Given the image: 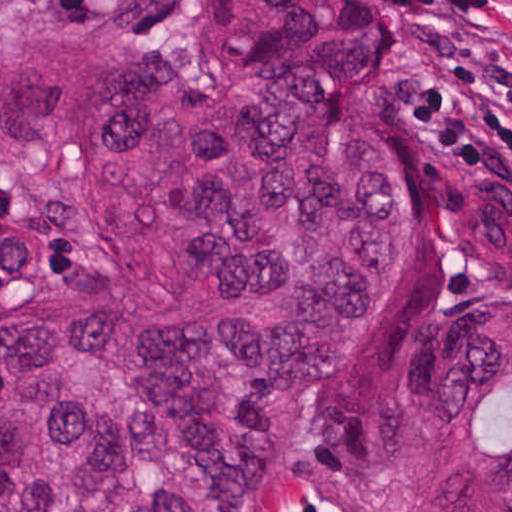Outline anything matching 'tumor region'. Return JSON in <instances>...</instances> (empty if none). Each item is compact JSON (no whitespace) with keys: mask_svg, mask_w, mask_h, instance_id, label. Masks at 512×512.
Segmentation results:
<instances>
[{"mask_svg":"<svg viewBox=\"0 0 512 512\" xmlns=\"http://www.w3.org/2000/svg\"><path fill=\"white\" fill-rule=\"evenodd\" d=\"M223 72L0 36V512H257L311 464L360 512H512V293L461 296L378 370L349 344L403 270L368 0H203ZM436 230L512 290V176Z\"/></svg>","mask_w":512,"mask_h":512,"instance_id":"obj_1","label":"tumor region"}]
</instances>
